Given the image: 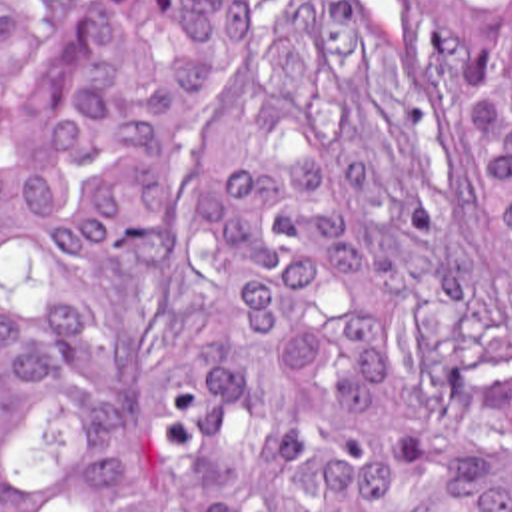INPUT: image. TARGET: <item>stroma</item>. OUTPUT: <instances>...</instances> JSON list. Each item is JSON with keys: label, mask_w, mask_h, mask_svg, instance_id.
I'll return each mask as SVG.
<instances>
[{"label": "stroma", "mask_w": 512, "mask_h": 512, "mask_svg": "<svg viewBox=\"0 0 512 512\" xmlns=\"http://www.w3.org/2000/svg\"><path fill=\"white\" fill-rule=\"evenodd\" d=\"M66 9H86L90 0H52ZM368 21L410 61L420 65L440 87L450 131L458 149L460 183L464 202L476 222V197L468 179L462 155V125L452 93V85L444 67L440 43L434 31V0H354Z\"/></svg>", "instance_id": "1"}]
</instances>
